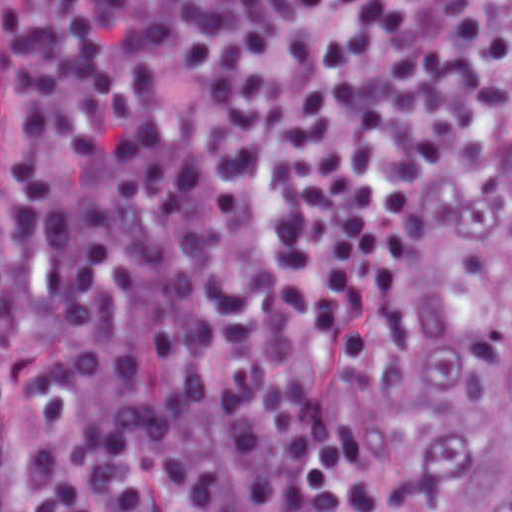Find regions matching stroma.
<instances>
[{"label":"stroma","instance_id":"stroma-1","mask_svg":"<svg viewBox=\"0 0 512 512\" xmlns=\"http://www.w3.org/2000/svg\"><path fill=\"white\" fill-rule=\"evenodd\" d=\"M1 14L0 0V512H20L30 505L31 444L37 416L23 390L9 378L1 383ZM303 367L327 406L347 417L354 426L366 476H400L413 450V431L408 420L373 388L356 390L338 381L337 359L324 345L312 343L303 348ZM444 494L448 511L461 512Z\"/></svg>","mask_w":512,"mask_h":512}]
</instances>
